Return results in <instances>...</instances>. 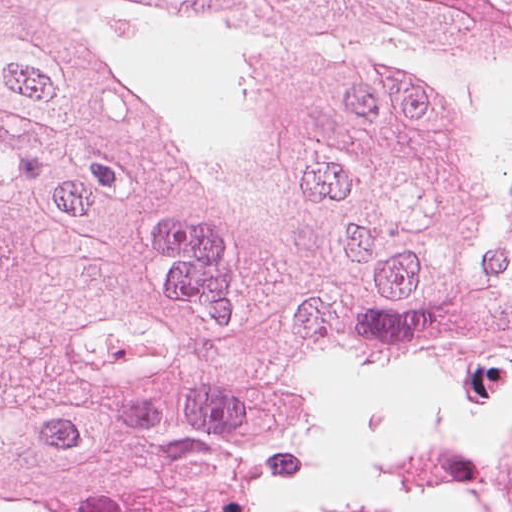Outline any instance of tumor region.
<instances>
[{
    "mask_svg": "<svg viewBox=\"0 0 512 512\" xmlns=\"http://www.w3.org/2000/svg\"><path fill=\"white\" fill-rule=\"evenodd\" d=\"M511 247L512 0H0V512L260 509Z\"/></svg>",
    "mask_w": 512,
    "mask_h": 512,
    "instance_id": "tumor-region-1",
    "label": "tumor region"
}]
</instances>
